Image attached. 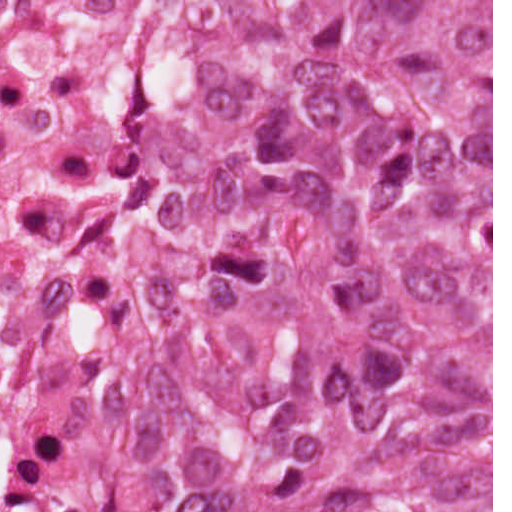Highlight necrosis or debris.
Listing matches in <instances>:
<instances>
[{"mask_svg":"<svg viewBox=\"0 0 512 512\" xmlns=\"http://www.w3.org/2000/svg\"><path fill=\"white\" fill-rule=\"evenodd\" d=\"M170 0H0V512H128L122 444L247 236L162 208L145 65Z\"/></svg>","mask_w":512,"mask_h":512,"instance_id":"necrosis-or-debris-1","label":"necrosis or debris"}]
</instances>
